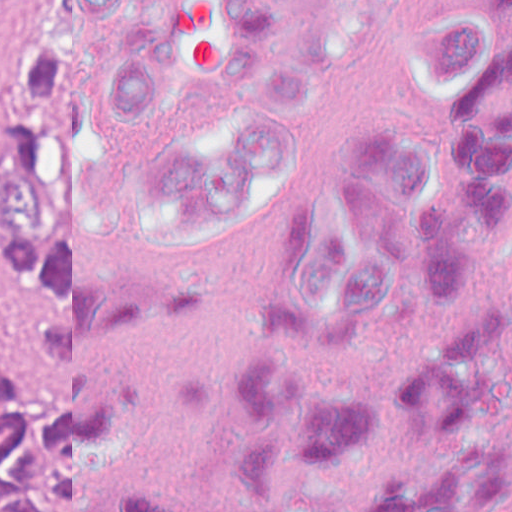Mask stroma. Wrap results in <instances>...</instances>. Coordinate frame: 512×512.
Returning a JSON list of instances; mask_svg holds the SVG:
<instances>
[{
  "label": "stroma",
  "mask_w": 512,
  "mask_h": 512,
  "mask_svg": "<svg viewBox=\"0 0 512 512\" xmlns=\"http://www.w3.org/2000/svg\"><path fill=\"white\" fill-rule=\"evenodd\" d=\"M17 0L0 3V167L15 113L13 16ZM33 335V301L0 255V355L28 344Z\"/></svg>",
  "instance_id": "obj_1"
}]
</instances>
